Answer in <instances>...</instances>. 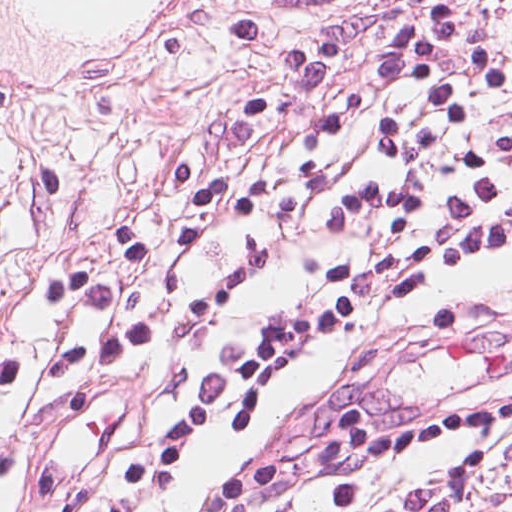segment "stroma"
<instances>
[{
	"label": "stroma",
	"mask_w": 512,
	"mask_h": 512,
	"mask_svg": "<svg viewBox=\"0 0 512 512\" xmlns=\"http://www.w3.org/2000/svg\"><path fill=\"white\" fill-rule=\"evenodd\" d=\"M393 0H202L188 40L156 71L89 112H21L0 102V349L19 358L14 420L19 445L0 512H33L40 462L33 430L47 371L76 325L39 309L44 282L122 220H172L171 182L201 160L254 87L281 65L309 28L329 18L322 91L273 167L271 193L181 274L161 332L127 366L79 385L52 414V440L106 445L143 399L185 392L199 346L193 304L210 281L234 287L219 333L233 335L295 292L309 268L287 237L286 214L307 171L324 165L371 174L370 125L382 95L355 131L332 137L326 120L374 72ZM222 435L200 439L177 471L167 512H198ZM450 440L389 453L388 490L407 512H512V436L489 459L474 497L446 495L440 480ZM304 512H335L321 500Z\"/></svg>",
	"instance_id": "obj_1"
}]
</instances>
